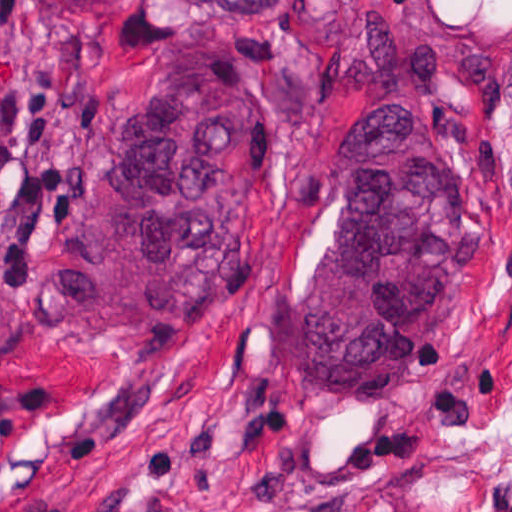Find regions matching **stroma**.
I'll return each mask as SVG.
<instances>
[{"instance_id":"1","label":"stroma","mask_w":512,"mask_h":512,"mask_svg":"<svg viewBox=\"0 0 512 512\" xmlns=\"http://www.w3.org/2000/svg\"><path fill=\"white\" fill-rule=\"evenodd\" d=\"M398 2L402 31L499 60L492 86L432 105L424 147L470 180L489 256L413 373L304 402L281 322L338 219L349 146L319 70L188 0H0V512H512V0ZM173 48H237L277 98L246 267L194 322L98 326L59 291L56 247Z\"/></svg>"}]
</instances>
